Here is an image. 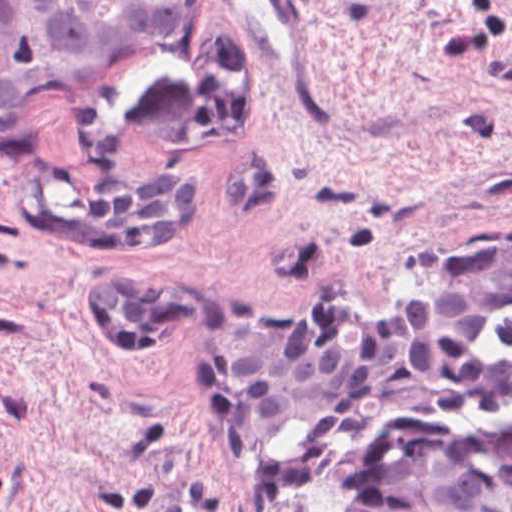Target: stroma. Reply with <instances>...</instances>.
Listing matches in <instances>:
<instances>
[{
  "label": "stroma",
  "mask_w": 512,
  "mask_h": 512,
  "mask_svg": "<svg viewBox=\"0 0 512 512\" xmlns=\"http://www.w3.org/2000/svg\"><path fill=\"white\" fill-rule=\"evenodd\" d=\"M0 153V512H356L362 456L413 420H512V311L480 357L508 394L367 425L342 456L252 483L227 405L235 321L322 298L374 312L443 256L512 240V0H182L171 31L30 104ZM203 179L197 234L76 250L38 219L115 182ZM219 299L159 341L97 332L92 280Z\"/></svg>",
  "instance_id": "35a3bbf8"
}]
</instances>
